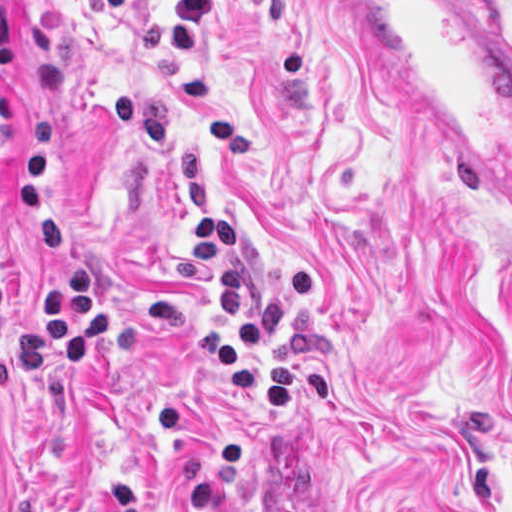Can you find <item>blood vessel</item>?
Here are the masks:
<instances>
[{
  "instance_id": "blood-vessel-1",
  "label": "blood vessel",
  "mask_w": 512,
  "mask_h": 512,
  "mask_svg": "<svg viewBox=\"0 0 512 512\" xmlns=\"http://www.w3.org/2000/svg\"><path fill=\"white\" fill-rule=\"evenodd\" d=\"M473 201L512 231V24L495 0H339Z\"/></svg>"
}]
</instances>
